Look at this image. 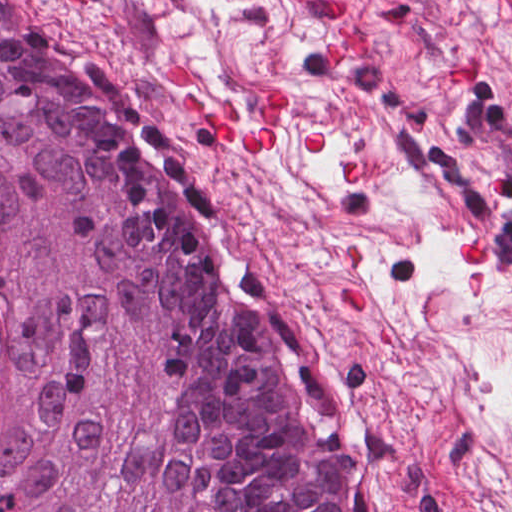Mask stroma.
Listing matches in <instances>:
<instances>
[{
	"mask_svg": "<svg viewBox=\"0 0 512 512\" xmlns=\"http://www.w3.org/2000/svg\"><path fill=\"white\" fill-rule=\"evenodd\" d=\"M36 1L196 161L228 273L372 512H512V0ZM350 25L368 56L331 65ZM176 62L239 127L277 83L276 150L237 155L191 120ZM315 132L328 147L306 153Z\"/></svg>",
	"mask_w": 512,
	"mask_h": 512,
	"instance_id": "stroma-1",
	"label": "stroma"
}]
</instances>
